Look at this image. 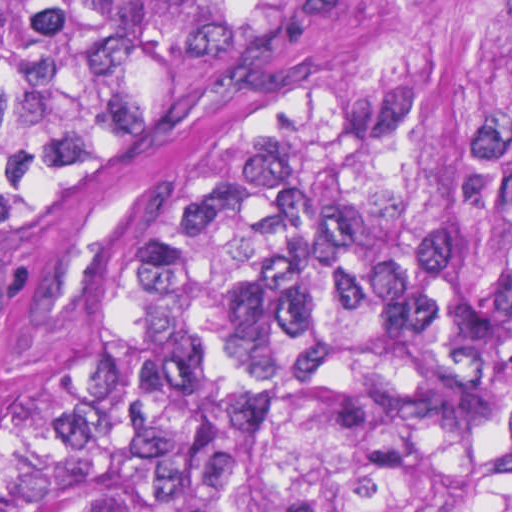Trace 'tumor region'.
<instances>
[{
	"mask_svg": "<svg viewBox=\"0 0 512 512\" xmlns=\"http://www.w3.org/2000/svg\"><path fill=\"white\" fill-rule=\"evenodd\" d=\"M0 512H512V0H0Z\"/></svg>",
	"mask_w": 512,
	"mask_h": 512,
	"instance_id": "obj_1",
	"label": "tumor region"
}]
</instances>
